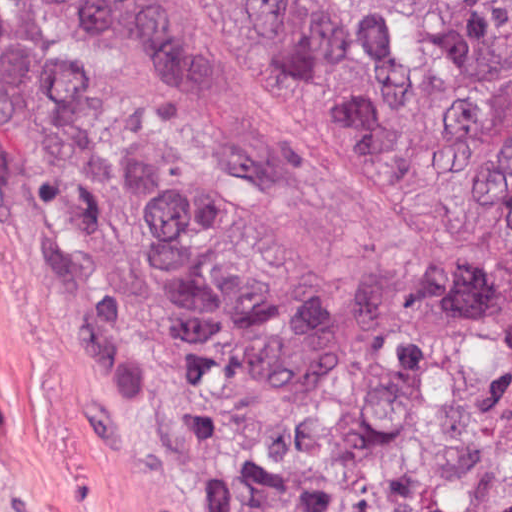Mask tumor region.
Instances as JSON below:
<instances>
[{"label": "tumor region", "instance_id": "tumor-region-1", "mask_svg": "<svg viewBox=\"0 0 512 512\" xmlns=\"http://www.w3.org/2000/svg\"><path fill=\"white\" fill-rule=\"evenodd\" d=\"M85 43L241 512H512V0H0Z\"/></svg>", "mask_w": 512, "mask_h": 512}]
</instances>
